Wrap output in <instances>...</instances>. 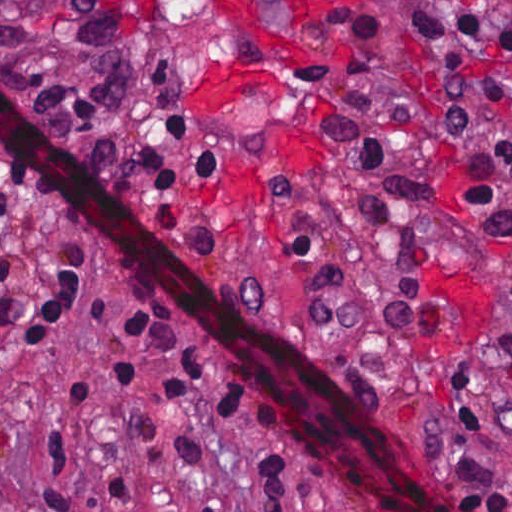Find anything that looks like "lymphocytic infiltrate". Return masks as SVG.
<instances>
[{
  "mask_svg": "<svg viewBox=\"0 0 512 512\" xmlns=\"http://www.w3.org/2000/svg\"><path fill=\"white\" fill-rule=\"evenodd\" d=\"M412 27L430 44H470L512 49V0L408 1ZM438 109L456 139L468 148L469 195L496 247L512 265V82L486 78L451 81L439 88ZM192 119L167 110L163 152L142 148L140 160L154 197L172 191L183 175H214L218 152L182 147ZM35 194L7 164L0 169V230L22 202ZM2 267L0 265V282ZM85 287L74 250L64 241L53 269L39 287L21 345L51 340L86 309ZM27 319L25 305L0 299V334ZM94 362L102 378L130 392L159 397L203 392L223 420L261 440L262 472L245 483L266 512H310L301 495L307 483L346 487L337 468L313 457L298 435L269 412L218 356L206 350L187 325L155 310L135 308L95 330ZM100 414L91 389L73 387L49 401L41 427L43 489L24 512H109L129 499L126 485L106 480L89 511L64 478L77 438ZM477 433V403L461 361L444 388L441 422L419 447L436 460L437 444L466 443ZM497 436L512 441V341L502 365V408ZM473 512H512L510 485L492 475L477 485L454 484Z\"/></svg>",
  "mask_w": 512,
  "mask_h": 512,
  "instance_id": "1",
  "label": "lymphocytic infiltrate"
}]
</instances>
